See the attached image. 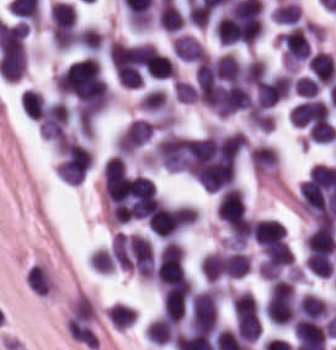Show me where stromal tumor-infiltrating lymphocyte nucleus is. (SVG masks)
I'll list each match as a JSON object with an SVG mask.
<instances>
[{"label": "stromal tumor-infiltrating lymphocyte nucleus", "instance_id": "stromal-tumor-infiltrating-lymphocyte-nucleus-1", "mask_svg": "<svg viewBox=\"0 0 336 350\" xmlns=\"http://www.w3.org/2000/svg\"><path fill=\"white\" fill-rule=\"evenodd\" d=\"M189 320L193 331L212 330L217 320V292L206 289L192 296L189 302Z\"/></svg>", "mask_w": 336, "mask_h": 350}, {"label": "stromal tumor-infiltrating lymphocyte nucleus", "instance_id": "stromal-tumor-infiltrating-lymphocyte-nucleus-2", "mask_svg": "<svg viewBox=\"0 0 336 350\" xmlns=\"http://www.w3.org/2000/svg\"><path fill=\"white\" fill-rule=\"evenodd\" d=\"M216 212L220 220L231 229H243L247 212L242 192L236 187H229L222 192Z\"/></svg>", "mask_w": 336, "mask_h": 350}, {"label": "stromal tumor-infiltrating lymphocyte nucleus", "instance_id": "stromal-tumor-infiltrating-lymphocyte-nucleus-3", "mask_svg": "<svg viewBox=\"0 0 336 350\" xmlns=\"http://www.w3.org/2000/svg\"><path fill=\"white\" fill-rule=\"evenodd\" d=\"M305 246L311 262L330 256L336 251L334 228L320 221L306 238Z\"/></svg>", "mask_w": 336, "mask_h": 350}, {"label": "stromal tumor-infiltrating lymphocyte nucleus", "instance_id": "stromal-tumor-infiltrating-lymphocyte-nucleus-4", "mask_svg": "<svg viewBox=\"0 0 336 350\" xmlns=\"http://www.w3.org/2000/svg\"><path fill=\"white\" fill-rule=\"evenodd\" d=\"M293 336L299 350H325L326 329L312 319H299L294 326Z\"/></svg>", "mask_w": 336, "mask_h": 350}, {"label": "stromal tumor-infiltrating lymphocyte nucleus", "instance_id": "stromal-tumor-infiltrating-lymphocyte-nucleus-5", "mask_svg": "<svg viewBox=\"0 0 336 350\" xmlns=\"http://www.w3.org/2000/svg\"><path fill=\"white\" fill-rule=\"evenodd\" d=\"M153 125L146 119H132L116 143V152L129 155L149 140Z\"/></svg>", "mask_w": 336, "mask_h": 350}, {"label": "stromal tumor-infiltrating lymphocyte nucleus", "instance_id": "stromal-tumor-infiltrating-lymphocyte-nucleus-6", "mask_svg": "<svg viewBox=\"0 0 336 350\" xmlns=\"http://www.w3.org/2000/svg\"><path fill=\"white\" fill-rule=\"evenodd\" d=\"M292 123L306 126L330 120L328 104L317 99H305L290 110Z\"/></svg>", "mask_w": 336, "mask_h": 350}, {"label": "stromal tumor-infiltrating lymphocyte nucleus", "instance_id": "stromal-tumor-infiltrating-lymphocyte-nucleus-7", "mask_svg": "<svg viewBox=\"0 0 336 350\" xmlns=\"http://www.w3.org/2000/svg\"><path fill=\"white\" fill-rule=\"evenodd\" d=\"M187 297L188 288L185 284L163 291L162 315L179 324L184 318Z\"/></svg>", "mask_w": 336, "mask_h": 350}, {"label": "stromal tumor-infiltrating lymphocyte nucleus", "instance_id": "stromal-tumor-infiltrating-lymphocyte-nucleus-8", "mask_svg": "<svg viewBox=\"0 0 336 350\" xmlns=\"http://www.w3.org/2000/svg\"><path fill=\"white\" fill-rule=\"evenodd\" d=\"M253 237L258 244L285 239L286 229L278 220H258L252 225Z\"/></svg>", "mask_w": 336, "mask_h": 350}, {"label": "stromal tumor-infiltrating lymphocyte nucleus", "instance_id": "stromal-tumor-infiltrating-lymphocyte-nucleus-9", "mask_svg": "<svg viewBox=\"0 0 336 350\" xmlns=\"http://www.w3.org/2000/svg\"><path fill=\"white\" fill-rule=\"evenodd\" d=\"M52 27L56 30L72 29L77 21V14L72 3L57 1L50 8Z\"/></svg>", "mask_w": 336, "mask_h": 350}, {"label": "stromal tumor-infiltrating lymphocyte nucleus", "instance_id": "stromal-tumor-infiltrating-lymphocyte-nucleus-10", "mask_svg": "<svg viewBox=\"0 0 336 350\" xmlns=\"http://www.w3.org/2000/svg\"><path fill=\"white\" fill-rule=\"evenodd\" d=\"M178 325L172 321L157 319L152 321L146 334L148 341L158 344L172 343L175 339Z\"/></svg>", "mask_w": 336, "mask_h": 350}, {"label": "stromal tumor-infiltrating lymphocyte nucleus", "instance_id": "stromal-tumor-infiltrating-lymphocyte-nucleus-11", "mask_svg": "<svg viewBox=\"0 0 336 350\" xmlns=\"http://www.w3.org/2000/svg\"><path fill=\"white\" fill-rule=\"evenodd\" d=\"M157 22L163 30L174 32L184 24V17L178 8L164 1L159 6Z\"/></svg>", "mask_w": 336, "mask_h": 350}, {"label": "stromal tumor-infiltrating lymphocyte nucleus", "instance_id": "stromal-tumor-infiltrating-lymphocyte-nucleus-12", "mask_svg": "<svg viewBox=\"0 0 336 350\" xmlns=\"http://www.w3.org/2000/svg\"><path fill=\"white\" fill-rule=\"evenodd\" d=\"M106 312L116 330H125L136 322V316L131 307L115 303Z\"/></svg>", "mask_w": 336, "mask_h": 350}, {"label": "stromal tumor-infiltrating lymphocyte nucleus", "instance_id": "stromal-tumor-infiltrating-lymphocyte-nucleus-13", "mask_svg": "<svg viewBox=\"0 0 336 350\" xmlns=\"http://www.w3.org/2000/svg\"><path fill=\"white\" fill-rule=\"evenodd\" d=\"M138 105L150 113H158L167 106L166 93L157 88L147 89L143 93Z\"/></svg>", "mask_w": 336, "mask_h": 350}, {"label": "stromal tumor-infiltrating lymphocyte nucleus", "instance_id": "stromal-tumor-infiltrating-lymphocyte-nucleus-14", "mask_svg": "<svg viewBox=\"0 0 336 350\" xmlns=\"http://www.w3.org/2000/svg\"><path fill=\"white\" fill-rule=\"evenodd\" d=\"M43 102L42 93L32 89H25L22 92L21 108L31 119L40 120Z\"/></svg>", "mask_w": 336, "mask_h": 350}, {"label": "stromal tumor-infiltrating lymphocyte nucleus", "instance_id": "stromal-tumor-infiltrating-lymphocyte-nucleus-15", "mask_svg": "<svg viewBox=\"0 0 336 350\" xmlns=\"http://www.w3.org/2000/svg\"><path fill=\"white\" fill-rule=\"evenodd\" d=\"M336 136V129L326 120H319L312 125L309 132V140L312 142H332Z\"/></svg>", "mask_w": 336, "mask_h": 350}, {"label": "stromal tumor-infiltrating lymphocyte nucleus", "instance_id": "stromal-tumor-infiltrating-lymphocyte-nucleus-16", "mask_svg": "<svg viewBox=\"0 0 336 350\" xmlns=\"http://www.w3.org/2000/svg\"><path fill=\"white\" fill-rule=\"evenodd\" d=\"M294 92L304 99H313L320 93V83L309 76H301L294 82Z\"/></svg>", "mask_w": 336, "mask_h": 350}]
</instances>
